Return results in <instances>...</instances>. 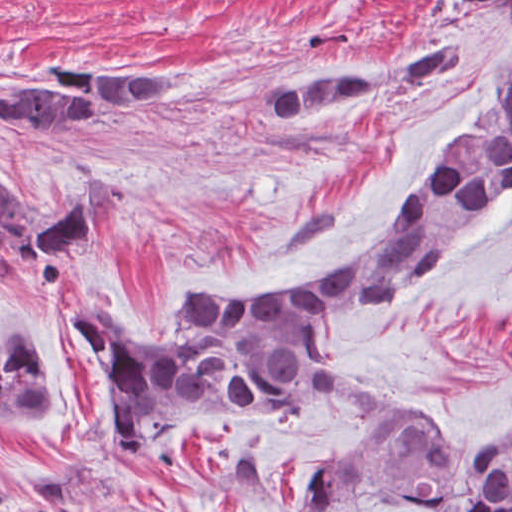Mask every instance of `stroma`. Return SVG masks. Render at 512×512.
<instances>
[{"instance_id": "stroma-1", "label": "stroma", "mask_w": 512, "mask_h": 512, "mask_svg": "<svg viewBox=\"0 0 512 512\" xmlns=\"http://www.w3.org/2000/svg\"><path fill=\"white\" fill-rule=\"evenodd\" d=\"M446 39L471 60L437 96L414 102L436 84L413 85L298 127L262 110L277 75L358 72ZM54 59L161 65L185 79V98L118 113L82 142L0 135V171L39 225L90 179L112 191L48 306L23 304L0 268V315L24 318L66 396L59 421L0 426V512H308L363 405L335 397L287 423L219 421L128 458L104 379L61 321L104 297L96 314L117 339L173 346L199 300L284 298L346 268L512 61V0H0V76ZM321 343L381 389L384 425L442 445L512 443V198L420 290L335 322Z\"/></svg>"}]
</instances>
